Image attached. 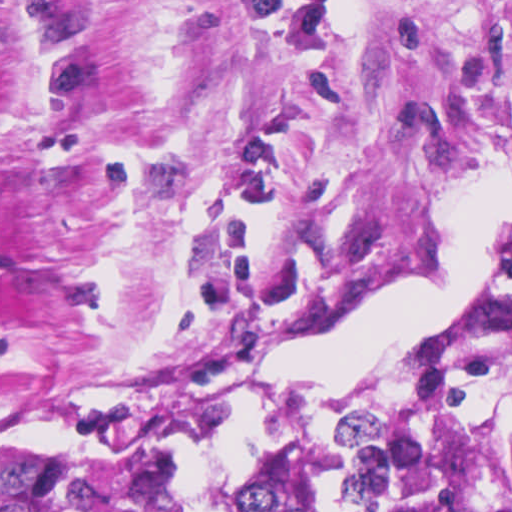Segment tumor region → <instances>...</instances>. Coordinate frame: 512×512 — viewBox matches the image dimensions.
I'll return each mask as SVG.
<instances>
[{
  "label": "tumor region",
  "instance_id": "1",
  "mask_svg": "<svg viewBox=\"0 0 512 512\" xmlns=\"http://www.w3.org/2000/svg\"><path fill=\"white\" fill-rule=\"evenodd\" d=\"M251 389L0 428V512H186L180 459L217 444ZM230 512H512V299L347 369L320 410L288 407Z\"/></svg>",
  "mask_w": 512,
  "mask_h": 512
}]
</instances>
